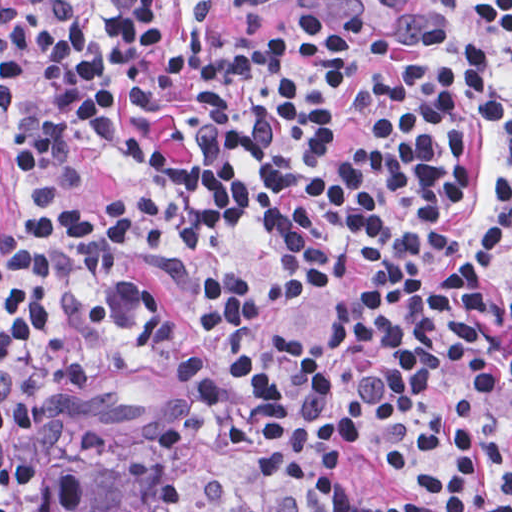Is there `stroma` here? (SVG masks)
Instances as JSON below:
<instances>
[{
  "mask_svg": "<svg viewBox=\"0 0 512 512\" xmlns=\"http://www.w3.org/2000/svg\"><path fill=\"white\" fill-rule=\"evenodd\" d=\"M300 0H214L216 24L234 34H264L287 23ZM398 41L449 62V44L481 52H502L501 77L508 87L512 44L480 17L468 0H326ZM483 160H507L506 126H481ZM18 132L0 117V231L21 234L22 188L16 154ZM130 257V256H129ZM141 278L163 304L164 314L187 323L188 287L196 264L181 259H135ZM483 270L497 292L510 300V248L483 255ZM332 309L316 302L279 296V307L254 335L250 346L319 358ZM180 388L156 363L143 342L103 367L89 384L88 407L104 421L98 449L80 451L73 418L27 441L28 455L60 457L82 475L75 512H105L146 495L159 483L181 492L173 512H246L252 466L242 454L197 444L161 447L157 431L178 414ZM461 512H483L465 508Z\"/></svg>",
  "mask_w": 512,
  "mask_h": 512,
  "instance_id": "obj_1",
  "label": "stroma"
}]
</instances>
